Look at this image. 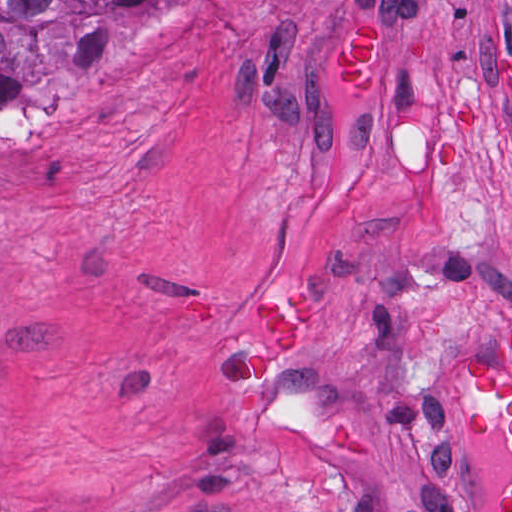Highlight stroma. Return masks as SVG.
<instances>
[{
    "instance_id": "1",
    "label": "stroma",
    "mask_w": 512,
    "mask_h": 512,
    "mask_svg": "<svg viewBox=\"0 0 512 512\" xmlns=\"http://www.w3.org/2000/svg\"><path fill=\"white\" fill-rule=\"evenodd\" d=\"M274 287L315 312L237 432ZM511 330L512 0H148L0 109V512H497L457 380Z\"/></svg>"
}]
</instances>
